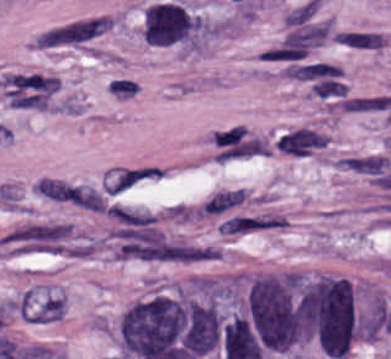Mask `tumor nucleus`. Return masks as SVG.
<instances>
[{
    "mask_svg": "<svg viewBox=\"0 0 391 359\" xmlns=\"http://www.w3.org/2000/svg\"><path fill=\"white\" fill-rule=\"evenodd\" d=\"M116 338L128 359H183L190 343L186 301L161 294L134 300L117 321Z\"/></svg>",
    "mask_w": 391,
    "mask_h": 359,
    "instance_id": "obj_1",
    "label": "tumor nucleus"
},
{
    "mask_svg": "<svg viewBox=\"0 0 391 359\" xmlns=\"http://www.w3.org/2000/svg\"><path fill=\"white\" fill-rule=\"evenodd\" d=\"M144 42L156 46L197 44L198 18L174 0L149 4L142 14Z\"/></svg>",
    "mask_w": 391,
    "mask_h": 359,
    "instance_id": "obj_2",
    "label": "tumor nucleus"
}]
</instances>
